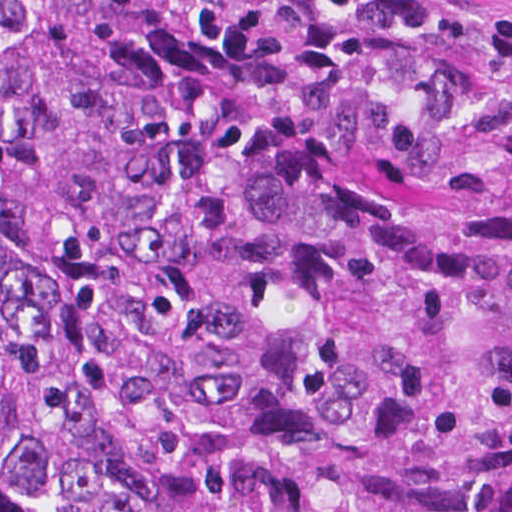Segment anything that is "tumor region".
<instances>
[{
    "instance_id": "tumor-region-1",
    "label": "tumor region",
    "mask_w": 512,
    "mask_h": 512,
    "mask_svg": "<svg viewBox=\"0 0 512 512\" xmlns=\"http://www.w3.org/2000/svg\"><path fill=\"white\" fill-rule=\"evenodd\" d=\"M0 512H512V0H0Z\"/></svg>"
}]
</instances>
